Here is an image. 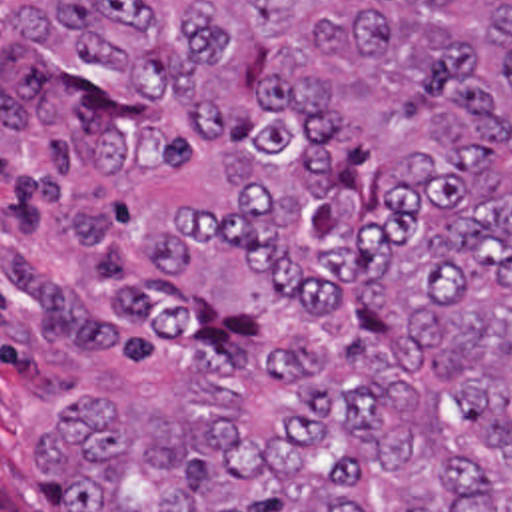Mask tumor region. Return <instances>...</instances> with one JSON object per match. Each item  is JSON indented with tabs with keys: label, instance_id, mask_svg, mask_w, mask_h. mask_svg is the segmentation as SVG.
I'll return each mask as SVG.
<instances>
[{
	"label": "tumor region",
	"instance_id": "obj_1",
	"mask_svg": "<svg viewBox=\"0 0 512 512\" xmlns=\"http://www.w3.org/2000/svg\"><path fill=\"white\" fill-rule=\"evenodd\" d=\"M0 155L144 370L68 512H512V0H0Z\"/></svg>",
	"mask_w": 512,
	"mask_h": 512
}]
</instances>
